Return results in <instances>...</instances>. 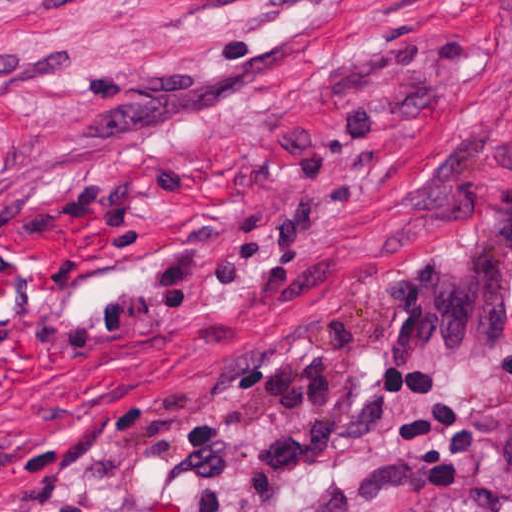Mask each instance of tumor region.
<instances>
[{"label": "tumor region", "mask_w": 512, "mask_h": 512, "mask_svg": "<svg viewBox=\"0 0 512 512\" xmlns=\"http://www.w3.org/2000/svg\"><path fill=\"white\" fill-rule=\"evenodd\" d=\"M374 301L395 320L407 362L497 345L512 325V181L488 187L482 218L465 230H411L381 270ZM507 405L480 421V437L489 457L512 471V336ZM434 512H512V495L502 486L471 489Z\"/></svg>", "instance_id": "1"}]
</instances>
